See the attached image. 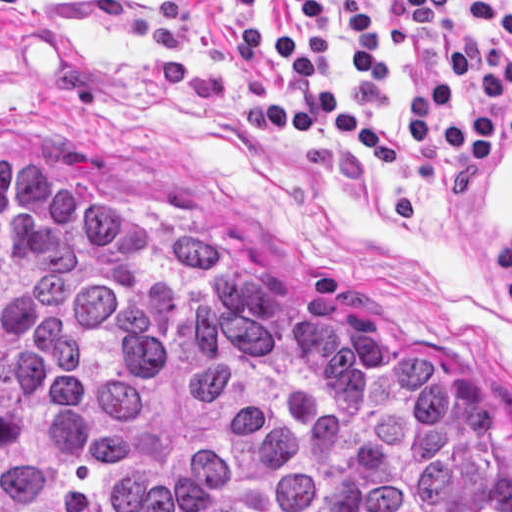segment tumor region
<instances>
[{"instance_id":"obj_1","label":"tumor region","mask_w":512,"mask_h":512,"mask_svg":"<svg viewBox=\"0 0 512 512\" xmlns=\"http://www.w3.org/2000/svg\"><path fill=\"white\" fill-rule=\"evenodd\" d=\"M0 512H512V467L440 355L0 159Z\"/></svg>"}]
</instances>
